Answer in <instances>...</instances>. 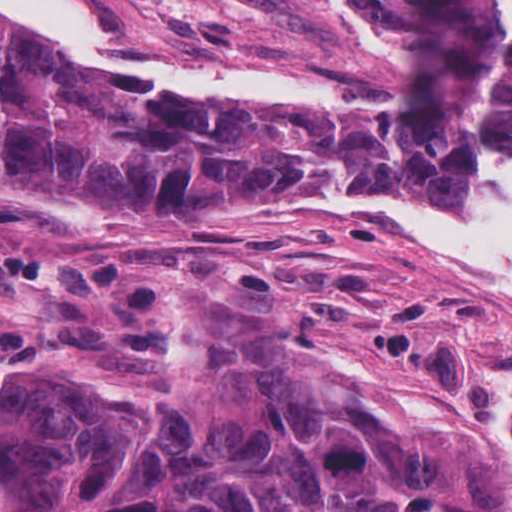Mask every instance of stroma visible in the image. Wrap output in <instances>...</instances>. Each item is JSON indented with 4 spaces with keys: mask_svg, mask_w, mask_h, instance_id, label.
Masks as SVG:
<instances>
[{
    "mask_svg": "<svg viewBox=\"0 0 512 512\" xmlns=\"http://www.w3.org/2000/svg\"><path fill=\"white\" fill-rule=\"evenodd\" d=\"M79 1L135 50L388 97V108L246 114L93 61L145 90L39 81L69 93L139 95L365 146L415 147L460 105L461 71L440 49L373 25L350 0ZM494 154L512 156V129L472 128L455 166L404 192L453 196ZM299 190L398 191L371 180L267 178L135 218L100 217L84 197L0 199V242L44 258L118 259L159 274L163 287L151 337H107L87 302L0 292V374L53 364L121 374L155 369L178 297L245 306L350 378L428 413L512 469V294L390 219L255 203Z\"/></svg>",
    "mask_w": 512,
    "mask_h": 512,
    "instance_id": "stroma-1",
    "label": "stroma"
}]
</instances>
